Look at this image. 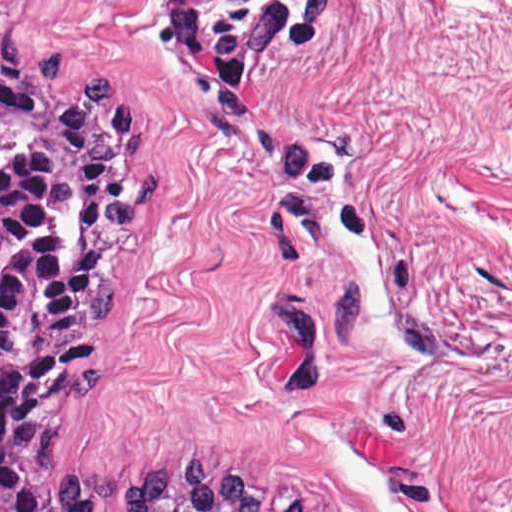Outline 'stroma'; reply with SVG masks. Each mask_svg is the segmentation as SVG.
I'll list each match as a JSON object with an SVG mask.
<instances>
[{
	"mask_svg": "<svg viewBox=\"0 0 512 512\" xmlns=\"http://www.w3.org/2000/svg\"><path fill=\"white\" fill-rule=\"evenodd\" d=\"M150 126L84 468L194 451L301 512H512V87L15 35Z\"/></svg>",
	"mask_w": 512,
	"mask_h": 512,
	"instance_id": "1",
	"label": "stroma"
}]
</instances>
